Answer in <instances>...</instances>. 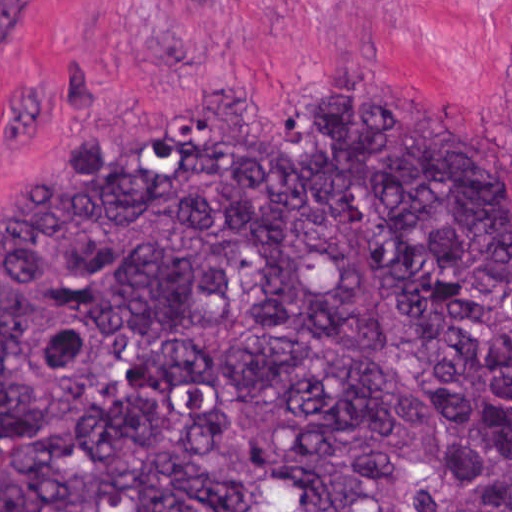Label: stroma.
I'll return each mask as SVG.
<instances>
[{
    "mask_svg": "<svg viewBox=\"0 0 512 512\" xmlns=\"http://www.w3.org/2000/svg\"><path fill=\"white\" fill-rule=\"evenodd\" d=\"M306 83L421 93L512 182V0H0V212L54 155L174 94L279 128Z\"/></svg>",
    "mask_w": 512,
    "mask_h": 512,
    "instance_id": "obj_1",
    "label": "stroma"
}]
</instances>
